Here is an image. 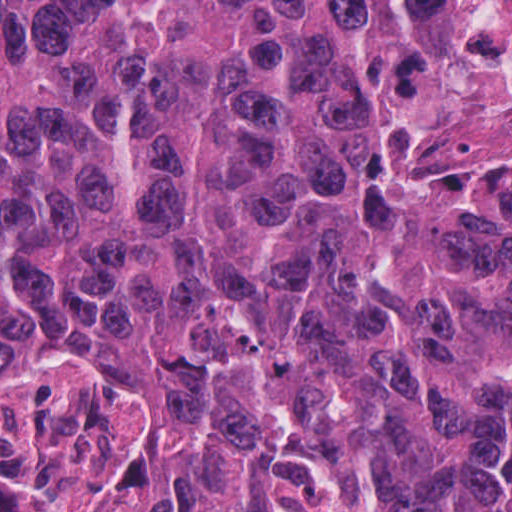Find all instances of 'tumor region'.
<instances>
[{
  "label": "tumor region",
  "instance_id": "e687c5a6",
  "mask_svg": "<svg viewBox=\"0 0 512 512\" xmlns=\"http://www.w3.org/2000/svg\"><path fill=\"white\" fill-rule=\"evenodd\" d=\"M53 359L145 410L88 512H512V212L363 150L356 0L0 15V386Z\"/></svg>",
  "mask_w": 512,
  "mask_h": 512
}]
</instances>
